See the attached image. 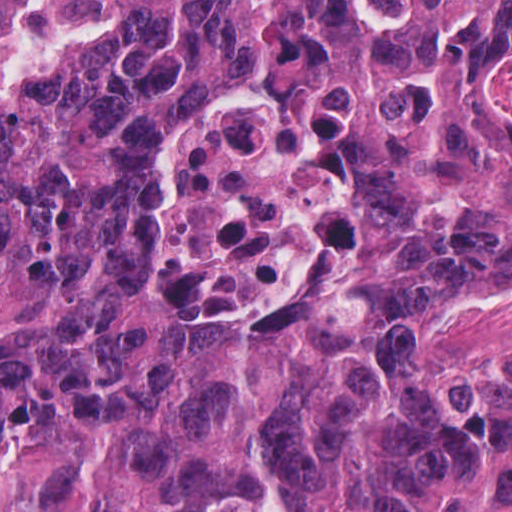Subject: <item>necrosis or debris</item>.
Listing matches in <instances>:
<instances>
[{
    "label": "necrosis or debris",
    "mask_w": 512,
    "mask_h": 512,
    "mask_svg": "<svg viewBox=\"0 0 512 512\" xmlns=\"http://www.w3.org/2000/svg\"><path fill=\"white\" fill-rule=\"evenodd\" d=\"M489 98L512 128V64ZM335 162L312 147L274 96L208 106L171 132L158 160L153 295L173 318L241 316L278 307L328 234ZM512 374V284L500 317L457 333L443 363L448 390L478 393Z\"/></svg>",
    "instance_id": "necrosis-or-debris-1"
}]
</instances>
